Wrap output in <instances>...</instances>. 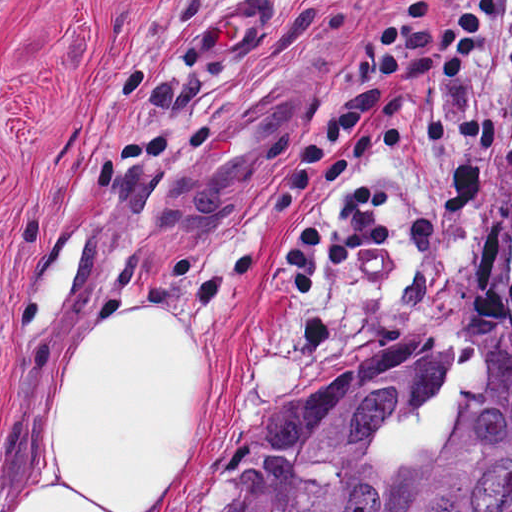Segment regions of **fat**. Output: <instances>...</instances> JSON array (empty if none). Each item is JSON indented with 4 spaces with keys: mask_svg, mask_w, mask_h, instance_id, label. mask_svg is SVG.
Instances as JSON below:
<instances>
[{
    "mask_svg": "<svg viewBox=\"0 0 512 512\" xmlns=\"http://www.w3.org/2000/svg\"><path fill=\"white\" fill-rule=\"evenodd\" d=\"M139 305L74 359L56 455L29 512H178L209 456L224 414L218 357Z\"/></svg>",
    "mask_w": 512,
    "mask_h": 512,
    "instance_id": "fat-1",
    "label": "fat"
}]
</instances>
